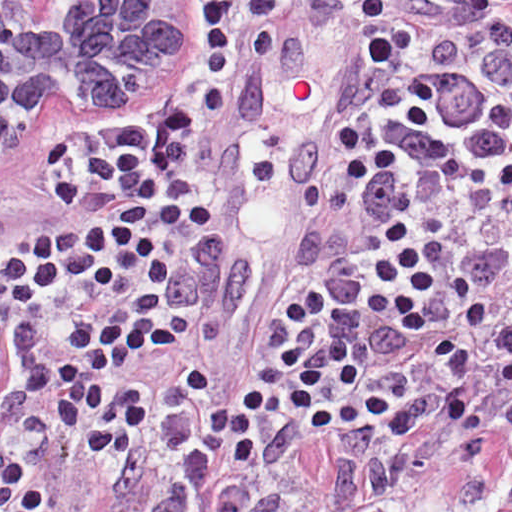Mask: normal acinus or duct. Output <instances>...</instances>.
<instances>
[{
    "mask_svg": "<svg viewBox=\"0 0 512 512\" xmlns=\"http://www.w3.org/2000/svg\"><path fill=\"white\" fill-rule=\"evenodd\" d=\"M183 13L185 1H0V154L134 110Z\"/></svg>",
    "mask_w": 512,
    "mask_h": 512,
    "instance_id": "obj_1",
    "label": "normal acinus or duct"
}]
</instances>
